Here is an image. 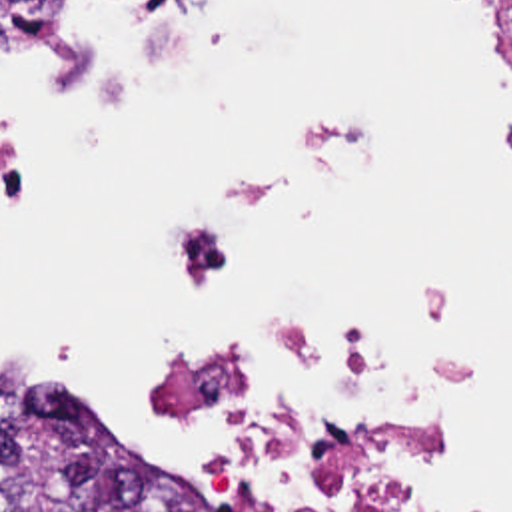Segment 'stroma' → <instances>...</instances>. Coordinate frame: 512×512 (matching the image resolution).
Masks as SVG:
<instances>
[{
  "label": "stroma",
  "mask_w": 512,
  "mask_h": 512,
  "mask_svg": "<svg viewBox=\"0 0 512 512\" xmlns=\"http://www.w3.org/2000/svg\"><path fill=\"white\" fill-rule=\"evenodd\" d=\"M493 1V0H491ZM493 5H495V1H493ZM495 11H497V17H499V21H501V25L507 29V25H505V19H503V15H501V11L497 9V5H495ZM164 414H166V418H168V422L172 424V428L174 430H178V432H182V434H188L166 410H164ZM110 442H114L106 432H102ZM116 444V442H114ZM222 462H226V464H230V466H234L236 470H240L242 474H246V476H250L252 480H254V484H256V488L262 492V496L266 498V500H270L280 512H286V500H284V494H282V488H280V482H278V478L276 476H272L268 470H264V468H260V466H256V464H250V462H246V460H222Z\"/></svg>",
  "instance_id": "stroma-1"
}]
</instances>
